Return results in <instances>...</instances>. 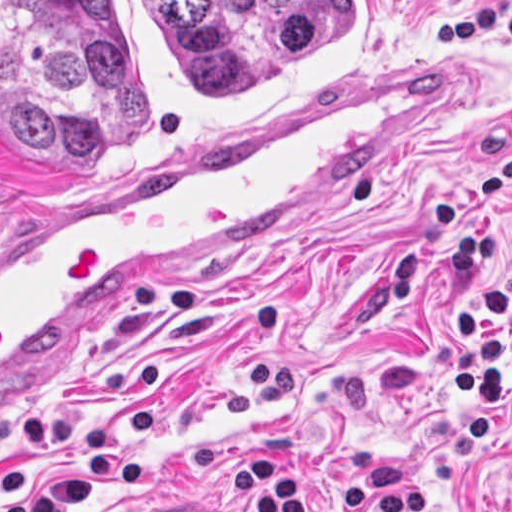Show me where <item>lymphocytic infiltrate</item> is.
<instances>
[{"mask_svg":"<svg viewBox=\"0 0 512 512\" xmlns=\"http://www.w3.org/2000/svg\"><path fill=\"white\" fill-rule=\"evenodd\" d=\"M512 210V156L480 186ZM449 261L453 278L478 283L458 312V401L455 421L434 437L425 458L408 466L392 443H365L345 453L348 472L332 493L336 512H458L423 502V491L455 473L492 424L512 354V276L489 277L500 259V242L461 193L433 199L417 230L388 260V301L400 311L417 283L424 251ZM506 482L512 486V463ZM508 512H512V507Z\"/></svg>","mask_w":512,"mask_h":512,"instance_id":"1","label":"lymphocytic infiltrate"}]
</instances>
